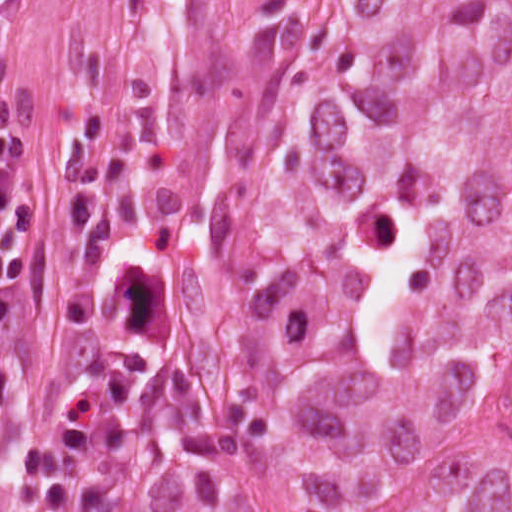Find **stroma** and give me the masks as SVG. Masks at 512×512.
Wrapping results in <instances>:
<instances>
[{"mask_svg": "<svg viewBox=\"0 0 512 512\" xmlns=\"http://www.w3.org/2000/svg\"><path fill=\"white\" fill-rule=\"evenodd\" d=\"M429 1L512 0H0V512H71L77 433L130 400L171 401L234 512H284L211 271L213 191L329 108L380 8Z\"/></svg>", "mask_w": 512, "mask_h": 512, "instance_id": "obj_1", "label": "stroma"}]
</instances>
